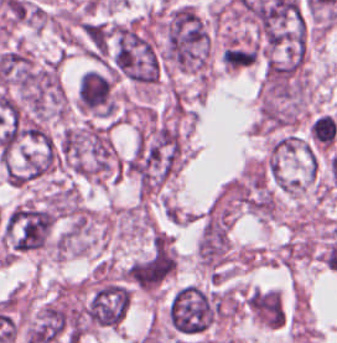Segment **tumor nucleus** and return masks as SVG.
<instances>
[{
  "label": "tumor nucleus",
  "instance_id": "tumor-nucleus-4",
  "mask_svg": "<svg viewBox=\"0 0 337 343\" xmlns=\"http://www.w3.org/2000/svg\"><path fill=\"white\" fill-rule=\"evenodd\" d=\"M54 213L44 205L24 201L13 208L3 222L7 251L33 253L43 248L50 239Z\"/></svg>",
  "mask_w": 337,
  "mask_h": 343
},
{
  "label": "tumor nucleus",
  "instance_id": "tumor-nucleus-3",
  "mask_svg": "<svg viewBox=\"0 0 337 343\" xmlns=\"http://www.w3.org/2000/svg\"><path fill=\"white\" fill-rule=\"evenodd\" d=\"M109 60L116 74L135 85L149 86L159 77L157 52L137 23H118L112 27Z\"/></svg>",
  "mask_w": 337,
  "mask_h": 343
},
{
  "label": "tumor nucleus",
  "instance_id": "tumor-nucleus-1",
  "mask_svg": "<svg viewBox=\"0 0 337 343\" xmlns=\"http://www.w3.org/2000/svg\"><path fill=\"white\" fill-rule=\"evenodd\" d=\"M181 161L182 143L175 126L156 123L139 137L122 163L143 189H156Z\"/></svg>",
  "mask_w": 337,
  "mask_h": 343
},
{
  "label": "tumor nucleus",
  "instance_id": "tumor-nucleus-2",
  "mask_svg": "<svg viewBox=\"0 0 337 343\" xmlns=\"http://www.w3.org/2000/svg\"><path fill=\"white\" fill-rule=\"evenodd\" d=\"M211 37L205 19L187 4H180L166 15L162 54L182 71L200 72L207 68Z\"/></svg>",
  "mask_w": 337,
  "mask_h": 343
}]
</instances>
